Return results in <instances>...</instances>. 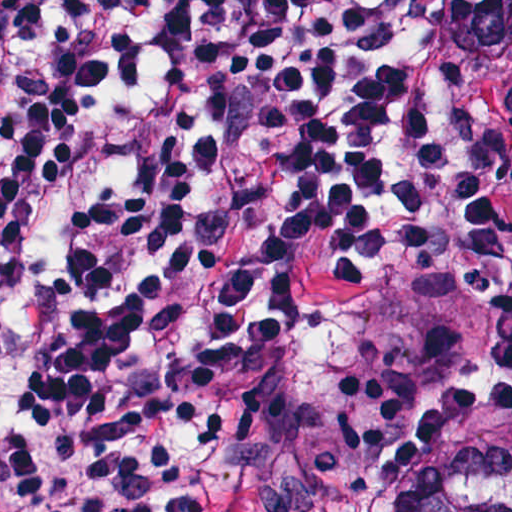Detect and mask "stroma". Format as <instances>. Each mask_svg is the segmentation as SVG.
<instances>
[{"label":"stroma","instance_id":"1","mask_svg":"<svg viewBox=\"0 0 512 512\" xmlns=\"http://www.w3.org/2000/svg\"><path fill=\"white\" fill-rule=\"evenodd\" d=\"M448 1L431 0L424 77L486 169L512 257V55L490 60L453 44L442 23ZM487 366H494L490 311L452 293L429 383L377 453L381 488L410 485L466 450L512 448V369L472 373Z\"/></svg>","mask_w":512,"mask_h":512}]
</instances>
